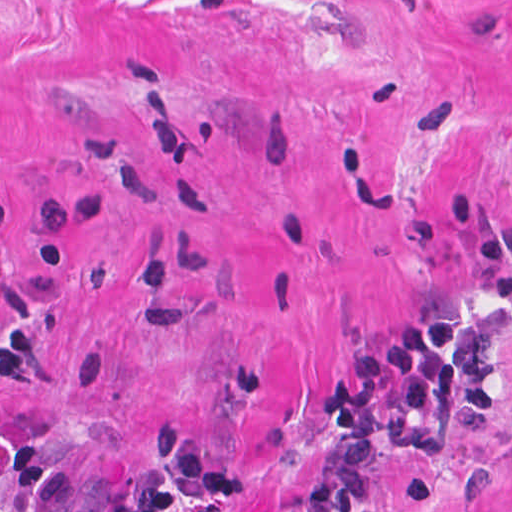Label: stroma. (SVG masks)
I'll use <instances>...</instances> for the list:
<instances>
[{"label": "stroma", "mask_w": 512, "mask_h": 512, "mask_svg": "<svg viewBox=\"0 0 512 512\" xmlns=\"http://www.w3.org/2000/svg\"><path fill=\"white\" fill-rule=\"evenodd\" d=\"M462 314L363 512H512V0H0V512H267L364 344Z\"/></svg>", "instance_id": "obj_1"}]
</instances>
